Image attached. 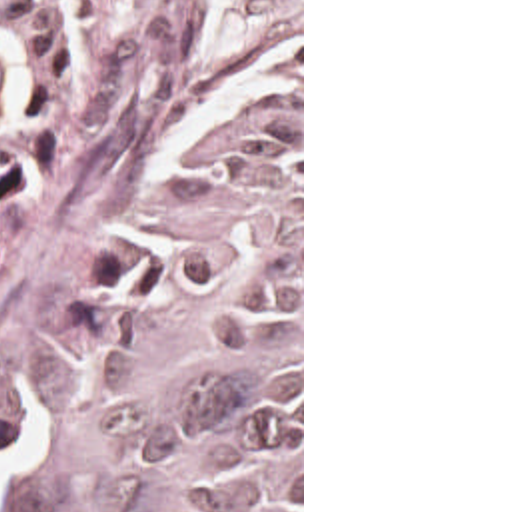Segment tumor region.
<instances>
[{
    "label": "tumor region",
    "instance_id": "e687c5a6",
    "mask_svg": "<svg viewBox=\"0 0 512 512\" xmlns=\"http://www.w3.org/2000/svg\"><path fill=\"white\" fill-rule=\"evenodd\" d=\"M98 0H0V188ZM6 512H300V72L222 110L208 194L136 236Z\"/></svg>",
    "mask_w": 512,
    "mask_h": 512
}]
</instances>
